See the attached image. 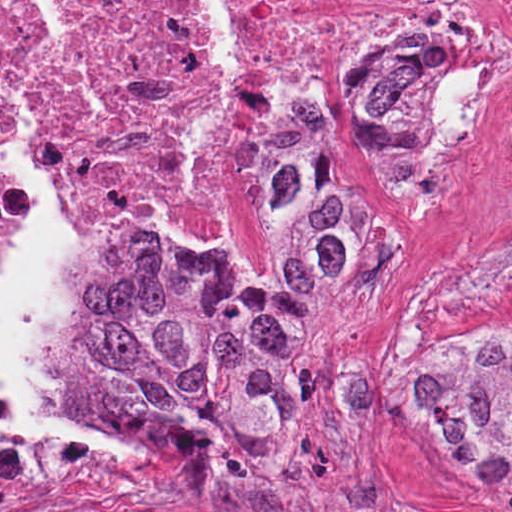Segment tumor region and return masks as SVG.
<instances>
[{"mask_svg": "<svg viewBox=\"0 0 512 512\" xmlns=\"http://www.w3.org/2000/svg\"><path fill=\"white\" fill-rule=\"evenodd\" d=\"M434 70L430 45L373 50L322 121L294 107L267 113L258 208L277 258L269 277L208 272L151 236L114 246L78 353L108 381L119 417L165 433L200 466L283 427L311 315L346 291L359 260V202L343 161L369 159L400 190L429 180L412 119ZM478 284L512 296V256ZM405 422L480 473H512V341L484 332L429 361L407 391Z\"/></svg>", "mask_w": 512, "mask_h": 512, "instance_id": "obj_1", "label": "tumor region"}]
</instances>
